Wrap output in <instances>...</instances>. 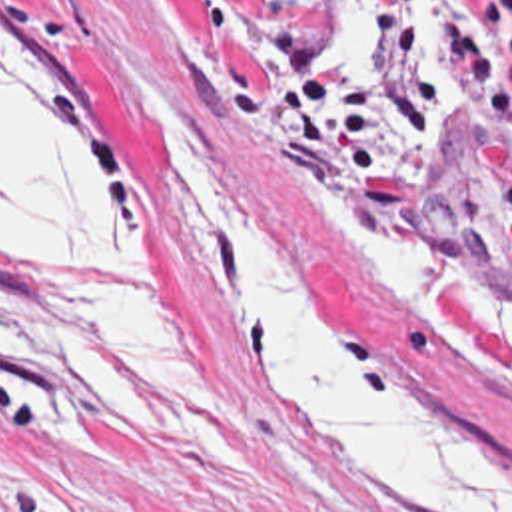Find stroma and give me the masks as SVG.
Segmentation results:
<instances>
[{
    "instance_id": "obj_1",
    "label": "stroma",
    "mask_w": 512,
    "mask_h": 512,
    "mask_svg": "<svg viewBox=\"0 0 512 512\" xmlns=\"http://www.w3.org/2000/svg\"><path fill=\"white\" fill-rule=\"evenodd\" d=\"M468 1L430 0L424 73H452L450 21L500 63L512 95V57L468 21ZM281 13L313 37L281 0H0L1 29L85 71L115 107L147 187L139 285L0 241V335L75 293H135L169 319L185 351L181 413H135L0 369V512H422L362 491L318 451L225 301L197 277L153 127L125 73L171 113L318 311L368 363L432 389L512 481V395L456 361L307 203L324 191L320 175L336 171L279 117L271 33ZM317 61L334 77L386 73L378 47L368 75L332 67L318 45ZM422 131L436 143L432 163L386 203V223L478 271L512 315V123L462 93ZM410 133L388 123L378 149Z\"/></svg>"
}]
</instances>
